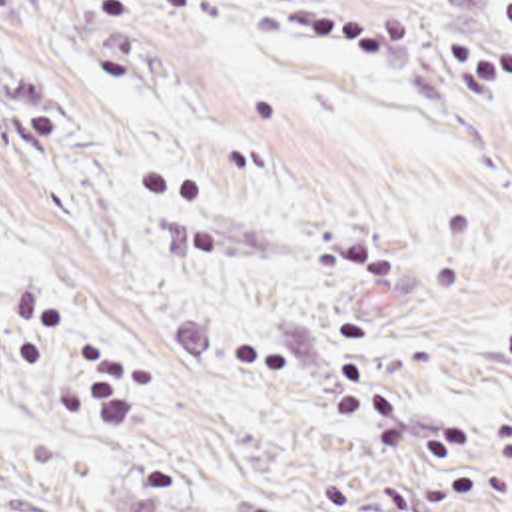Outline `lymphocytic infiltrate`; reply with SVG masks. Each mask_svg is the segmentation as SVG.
I'll return each mask as SVG.
<instances>
[{"instance_id": "f902f5d3", "label": "lymphocytic infiltrate", "mask_w": 512, "mask_h": 512, "mask_svg": "<svg viewBox=\"0 0 512 512\" xmlns=\"http://www.w3.org/2000/svg\"><path fill=\"white\" fill-rule=\"evenodd\" d=\"M502 16L508 30L504 44L492 46L474 34L450 30L440 34V48L478 82L512 96V0L504 2ZM63 332L65 322L55 302L43 304L15 340L21 369L41 379L51 399L61 405L85 407L99 419L131 417L151 391V365L123 353L115 340L85 338L75 371L55 381L53 361Z\"/></svg>"}]
</instances>
